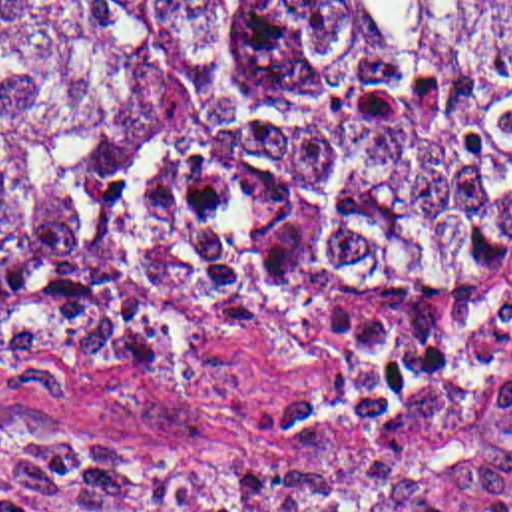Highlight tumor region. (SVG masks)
I'll use <instances>...</instances> for the list:
<instances>
[{"label": "tumor region", "instance_id": "1", "mask_svg": "<svg viewBox=\"0 0 512 512\" xmlns=\"http://www.w3.org/2000/svg\"><path fill=\"white\" fill-rule=\"evenodd\" d=\"M512 0H0V380L111 388L308 298L346 378L242 410L328 512L512 494ZM0 418V512H314Z\"/></svg>", "mask_w": 512, "mask_h": 512}]
</instances>
